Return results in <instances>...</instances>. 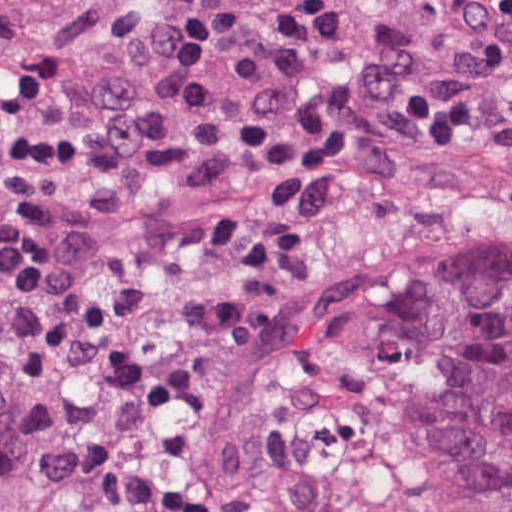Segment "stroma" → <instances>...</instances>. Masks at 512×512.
<instances>
[{
	"mask_svg": "<svg viewBox=\"0 0 512 512\" xmlns=\"http://www.w3.org/2000/svg\"><path fill=\"white\" fill-rule=\"evenodd\" d=\"M365 0L334 48L242 60L228 86L277 128L271 145L191 188L80 173L65 202L96 284L144 293L137 313L78 362V382L107 391L169 320L189 255L221 212L274 206L310 234L305 287L272 339L215 395L204 419L171 436L118 486H156L305 408L344 357L489 267H512V141L438 147L353 144L309 158L283 154L279 128L331 97L353 61ZM509 7L512 0H484ZM251 0H0V105L28 75L124 23L172 8ZM8 212L0 166V231ZM18 418L0 385V488L65 486L11 451Z\"/></svg>",
	"mask_w": 512,
	"mask_h": 512,
	"instance_id": "35a3bbf8",
	"label": "stroma"
}]
</instances>
